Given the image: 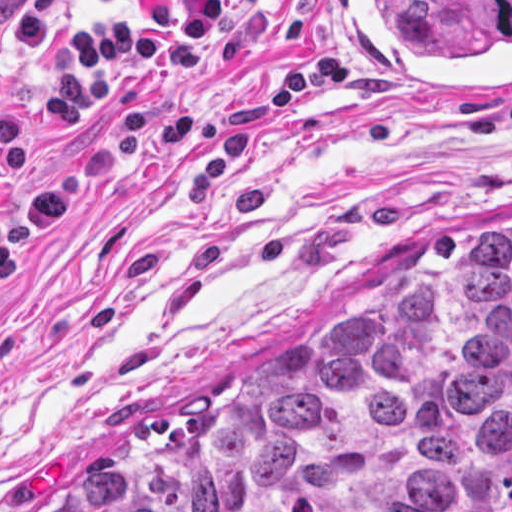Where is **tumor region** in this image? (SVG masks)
I'll use <instances>...</instances> for the list:
<instances>
[{"instance_id": "e687c5a6", "label": "tumor region", "mask_w": 512, "mask_h": 512, "mask_svg": "<svg viewBox=\"0 0 512 512\" xmlns=\"http://www.w3.org/2000/svg\"><path fill=\"white\" fill-rule=\"evenodd\" d=\"M63 512H512V235L252 372Z\"/></svg>"}]
</instances>
